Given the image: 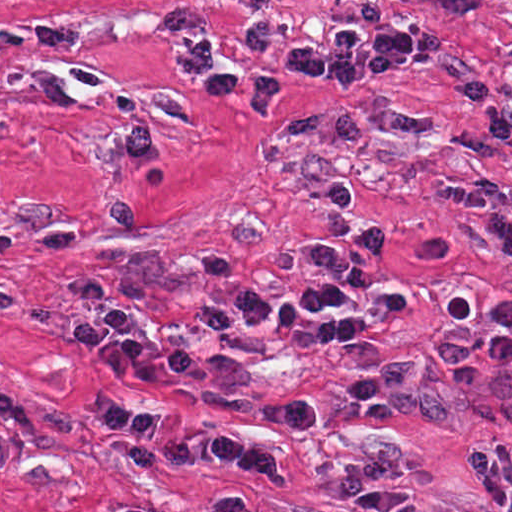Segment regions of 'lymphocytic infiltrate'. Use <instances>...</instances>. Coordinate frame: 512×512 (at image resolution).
I'll return each instance as SVG.
<instances>
[{
    "instance_id": "lymphocytic-infiltrate-1",
    "label": "lymphocytic infiltrate",
    "mask_w": 512,
    "mask_h": 512,
    "mask_svg": "<svg viewBox=\"0 0 512 512\" xmlns=\"http://www.w3.org/2000/svg\"><path fill=\"white\" fill-rule=\"evenodd\" d=\"M440 53V33L428 26L361 25L339 22L313 41L275 47L266 64L230 65L214 61L210 40L197 36L183 55L181 72L217 101H245L256 116H268L275 100L295 79L322 81L341 89L375 75L414 71ZM386 245L374 228L329 251H310L301 263L311 277L309 289L295 296L237 294L193 312L187 342L172 343L139 334L116 306L85 310L75 322L78 338L101 354L108 375L89 393L92 416L108 426L122 448L146 466L210 461L248 470L265 481H279L276 453L231 432H194L165 428L158 409L122 402L126 385H152L163 375L191 373L220 387H235L250 371L249 360L211 354V343L237 333H285L300 326L325 303L361 314L408 311L406 294L391 290L367 295L366 258ZM329 501L358 512H469L420 497L377 475L349 469L331 482Z\"/></svg>"
}]
</instances>
